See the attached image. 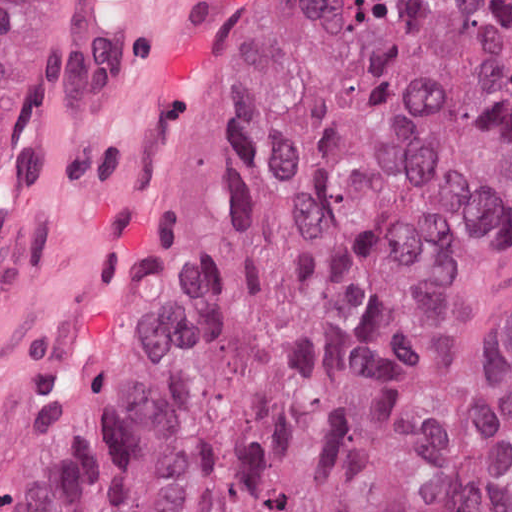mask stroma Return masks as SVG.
<instances>
[{
  "instance_id": "stroma-1",
  "label": "stroma",
  "mask_w": 512,
  "mask_h": 512,
  "mask_svg": "<svg viewBox=\"0 0 512 512\" xmlns=\"http://www.w3.org/2000/svg\"><path fill=\"white\" fill-rule=\"evenodd\" d=\"M268 0H252L220 92L188 154L178 198L96 359L82 376L29 512H56L97 415L123 394L175 322L221 179L233 108ZM113 0H46L42 81L23 166L0 218V300L12 284L77 120ZM420 333L443 409L512 488V208L454 247L427 281Z\"/></svg>"
}]
</instances>
